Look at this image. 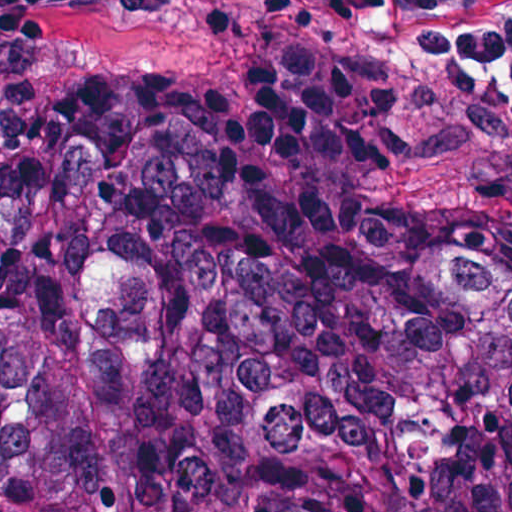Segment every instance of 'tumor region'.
I'll return each mask as SVG.
<instances>
[{
    "mask_svg": "<svg viewBox=\"0 0 512 512\" xmlns=\"http://www.w3.org/2000/svg\"><path fill=\"white\" fill-rule=\"evenodd\" d=\"M0 512H512V249L275 125L0 177Z\"/></svg>",
    "mask_w": 512,
    "mask_h": 512,
    "instance_id": "obj_1",
    "label": "tumor region"
}]
</instances>
